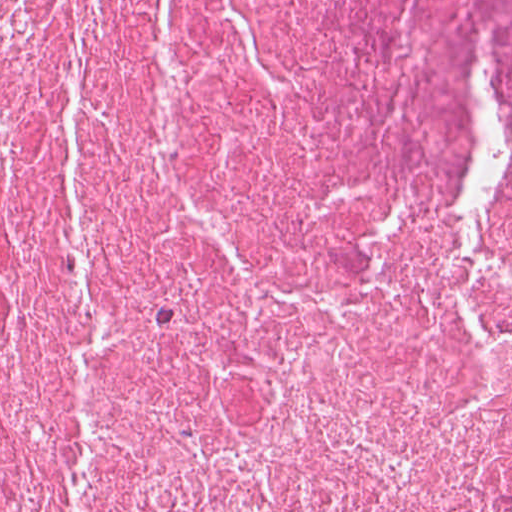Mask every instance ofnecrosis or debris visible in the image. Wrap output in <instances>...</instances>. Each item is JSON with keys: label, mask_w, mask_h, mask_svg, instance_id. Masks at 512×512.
Instances as JSON below:
<instances>
[{"label": "necrosis or debris", "mask_w": 512, "mask_h": 512, "mask_svg": "<svg viewBox=\"0 0 512 512\" xmlns=\"http://www.w3.org/2000/svg\"><path fill=\"white\" fill-rule=\"evenodd\" d=\"M0 512H512V0H0Z\"/></svg>", "instance_id": "necrosis-or-debris-1"}]
</instances>
